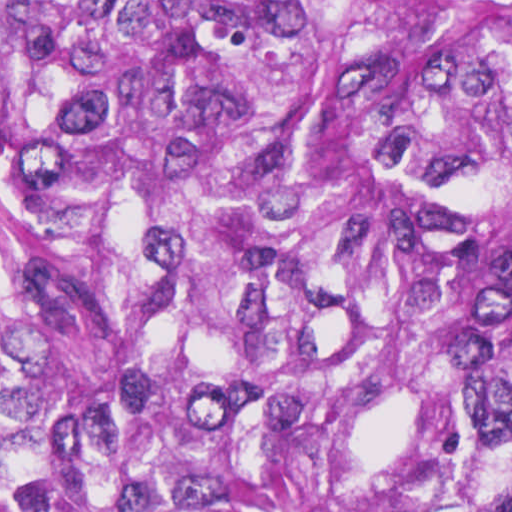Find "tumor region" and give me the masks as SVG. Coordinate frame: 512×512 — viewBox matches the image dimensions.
I'll list each match as a JSON object with an SVG mask.
<instances>
[{"mask_svg":"<svg viewBox=\"0 0 512 512\" xmlns=\"http://www.w3.org/2000/svg\"><path fill=\"white\" fill-rule=\"evenodd\" d=\"M0 512H512V0H0Z\"/></svg>","mask_w":512,"mask_h":512,"instance_id":"e687c5a6","label":"tumor region"}]
</instances>
